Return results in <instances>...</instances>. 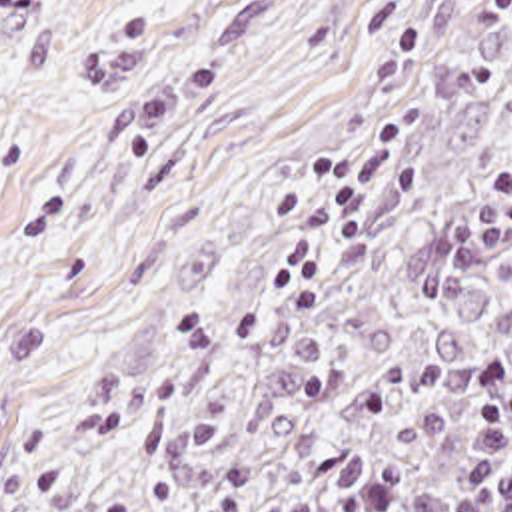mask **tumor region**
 <instances>
[{"instance_id": "obj_1", "label": "tumor region", "mask_w": 512, "mask_h": 512, "mask_svg": "<svg viewBox=\"0 0 512 512\" xmlns=\"http://www.w3.org/2000/svg\"><path fill=\"white\" fill-rule=\"evenodd\" d=\"M400 182L232 326L66 512H334L388 473L462 483L479 374L512 364V44Z\"/></svg>"}]
</instances>
